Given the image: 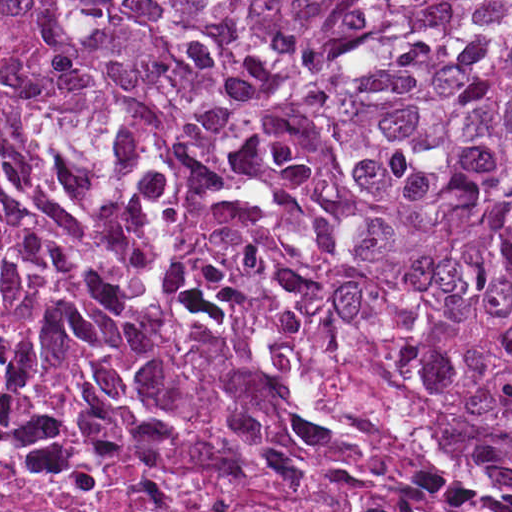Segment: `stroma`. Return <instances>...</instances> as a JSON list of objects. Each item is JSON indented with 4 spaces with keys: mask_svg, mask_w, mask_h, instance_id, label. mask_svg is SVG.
<instances>
[{
    "mask_svg": "<svg viewBox=\"0 0 512 512\" xmlns=\"http://www.w3.org/2000/svg\"><path fill=\"white\" fill-rule=\"evenodd\" d=\"M0 38L18 46L56 80L71 109L79 140L90 164L119 185L127 200L138 207L172 244L202 269L239 284L257 287L334 324L353 337L386 377L423 409L477 433L504 435L512 440L511 429L459 413L428 385L416 381L405 371L386 344L321 304L246 269H232L211 254L184 241L155 200L126 129L114 114L105 95L81 71L60 58L40 34L28 28L0 23Z\"/></svg>",
    "mask_w": 512,
    "mask_h": 512,
    "instance_id": "1",
    "label": "stroma"
}]
</instances>
